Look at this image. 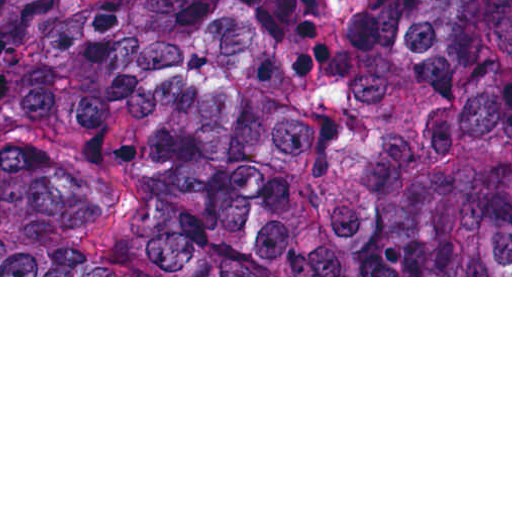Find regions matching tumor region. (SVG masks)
<instances>
[{
    "label": "tumor region",
    "mask_w": 512,
    "mask_h": 512,
    "mask_svg": "<svg viewBox=\"0 0 512 512\" xmlns=\"http://www.w3.org/2000/svg\"><path fill=\"white\" fill-rule=\"evenodd\" d=\"M512 268V0H0V275Z\"/></svg>",
    "instance_id": "e687c5a6"
}]
</instances>
